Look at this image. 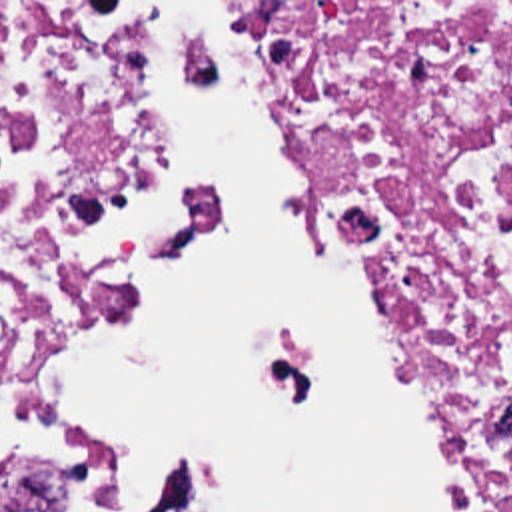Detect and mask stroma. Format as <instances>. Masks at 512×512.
<instances>
[{"instance_id": "1", "label": "stroma", "mask_w": 512, "mask_h": 512, "mask_svg": "<svg viewBox=\"0 0 512 512\" xmlns=\"http://www.w3.org/2000/svg\"><path fill=\"white\" fill-rule=\"evenodd\" d=\"M0 2H512V0H0ZM192 72H194V62H192ZM381 301H383L385 309L389 311V307H387L383 297H381Z\"/></svg>"}]
</instances>
